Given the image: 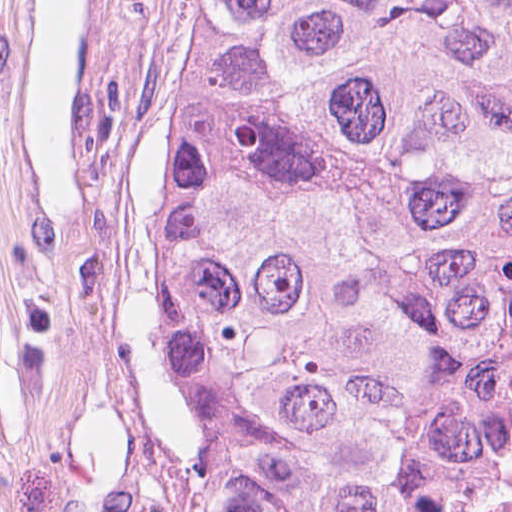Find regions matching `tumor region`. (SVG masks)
I'll return each instance as SVG.
<instances>
[{"instance_id": "e687c5a6", "label": "tumor region", "mask_w": 512, "mask_h": 512, "mask_svg": "<svg viewBox=\"0 0 512 512\" xmlns=\"http://www.w3.org/2000/svg\"><path fill=\"white\" fill-rule=\"evenodd\" d=\"M167 161L136 512H425L512 290V0H135L95 323Z\"/></svg>"}]
</instances>
